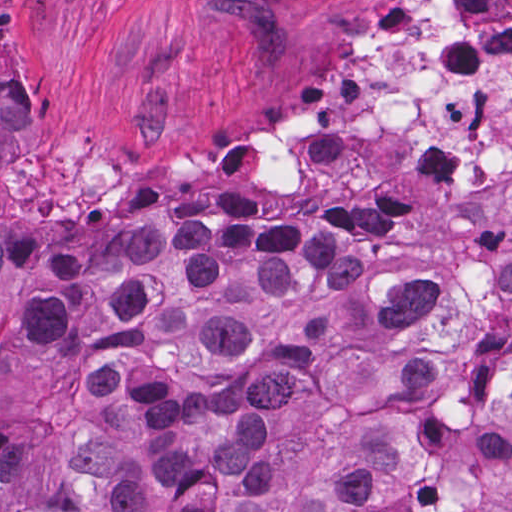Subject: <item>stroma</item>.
Listing matches in <instances>:
<instances>
[{"label": "stroma", "mask_w": 512, "mask_h": 512, "mask_svg": "<svg viewBox=\"0 0 512 512\" xmlns=\"http://www.w3.org/2000/svg\"><path fill=\"white\" fill-rule=\"evenodd\" d=\"M389 1L0 0V65L21 84L15 231L52 246L92 234L134 243L210 219L418 243L477 226L512 193V175L411 215L381 199L270 193L19 199L32 170L217 164L226 129L265 131L282 104L333 90Z\"/></svg>", "instance_id": "obj_1"}]
</instances>
